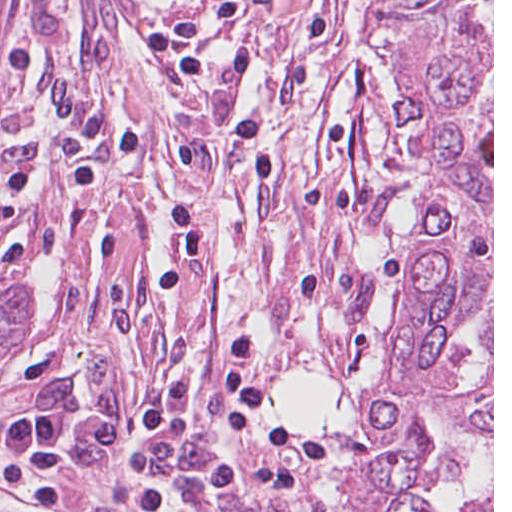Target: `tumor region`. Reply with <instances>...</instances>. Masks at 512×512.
<instances>
[{
  "mask_svg": "<svg viewBox=\"0 0 512 512\" xmlns=\"http://www.w3.org/2000/svg\"><path fill=\"white\" fill-rule=\"evenodd\" d=\"M10 20V0H0V38ZM38 309V287L23 279L0 299V361Z\"/></svg>",
  "mask_w": 512,
  "mask_h": 512,
  "instance_id": "1",
  "label": "tumor region"
}]
</instances>
